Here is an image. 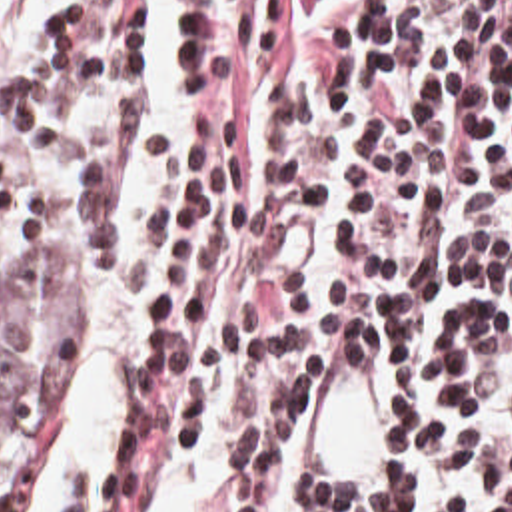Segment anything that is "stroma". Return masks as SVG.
<instances>
[{
    "instance_id": "1",
    "label": "stroma",
    "mask_w": 512,
    "mask_h": 512,
    "mask_svg": "<svg viewBox=\"0 0 512 512\" xmlns=\"http://www.w3.org/2000/svg\"><path fill=\"white\" fill-rule=\"evenodd\" d=\"M27 295H33V293L27 291L15 279H11L9 275L0 271V297H27ZM80 385H82V381H80V377H76V381L70 385V389L62 395V399L55 405V409L35 428L29 430V434L25 438V446H23V466H21V470H19V474L13 482L29 478V476L35 474V470H37V466H39V462H41V458H43V454H45V450H47V446H49V442H51V438H53V434L59 426L64 411L68 409L70 401L78 393Z\"/></svg>"
}]
</instances>
